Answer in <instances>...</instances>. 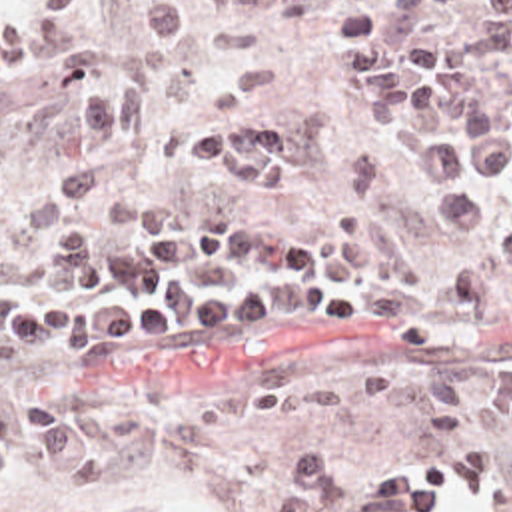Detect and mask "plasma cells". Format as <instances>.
Returning a JSON list of instances; mask_svg holds the SVG:
<instances>
[{
    "mask_svg": "<svg viewBox=\"0 0 512 512\" xmlns=\"http://www.w3.org/2000/svg\"><path fill=\"white\" fill-rule=\"evenodd\" d=\"M236 2L138 0L128 62L118 78L88 88L80 150L46 182L54 198L104 192L130 110L188 36ZM281 2L254 0L256 8ZM393 4V18L343 10L335 20L347 112L365 128H391L405 110L433 122L407 130L401 152L427 186L439 224L469 234L487 220L483 192L512 186V98L497 96L477 50L451 30L463 14L512 26V0ZM178 152L242 188H283L311 170V140L295 122L230 124L180 142ZM18 256L0 240V364L22 358L102 370L118 354L206 320L351 324L409 342L483 320L512 300V244L439 276L397 234L359 216L329 222L317 242L293 224L230 212L210 192L142 194L108 206L94 230L62 232L44 286L6 278L2 270ZM84 418V402L0 386V482H10L26 454L56 492L110 488V456ZM285 476L293 486L269 500V512H451L459 498L512 512V480L487 442L449 460L415 462L369 488L341 484L331 450L293 458Z\"/></svg>",
    "mask_w": 512,
    "mask_h": 512,
    "instance_id": "9512152a",
    "label": "plasma cells"
}]
</instances>
